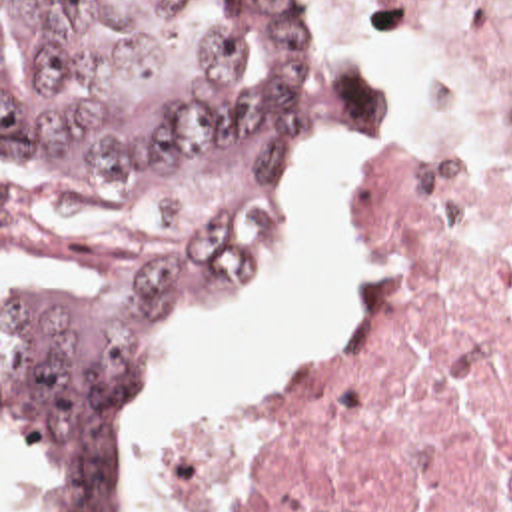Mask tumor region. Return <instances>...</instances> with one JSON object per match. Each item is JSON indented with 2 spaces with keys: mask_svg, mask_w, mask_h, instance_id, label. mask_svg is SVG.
<instances>
[{
  "mask_svg": "<svg viewBox=\"0 0 512 512\" xmlns=\"http://www.w3.org/2000/svg\"><path fill=\"white\" fill-rule=\"evenodd\" d=\"M373 132V84L302 0H2V160L154 186L230 160L240 192L90 290L2 304V422L56 474L36 512H134L128 422L168 336L234 298L300 152Z\"/></svg>",
  "mask_w": 512,
  "mask_h": 512,
  "instance_id": "1",
  "label": "tumor region"
}]
</instances>
